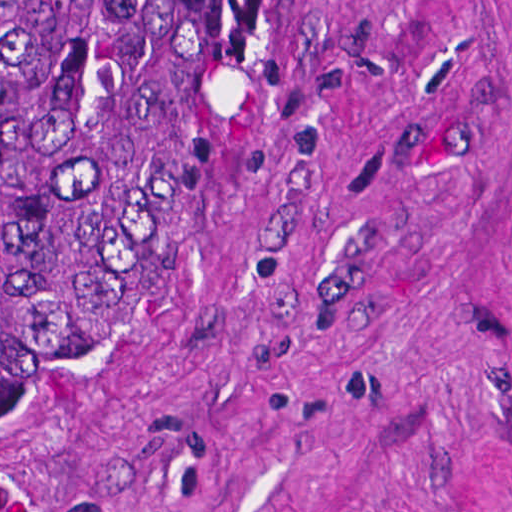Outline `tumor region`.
I'll list each match as a JSON object with an SVG mask.
<instances>
[{
  "instance_id": "tumor-region-1",
  "label": "tumor region",
  "mask_w": 512,
  "mask_h": 512,
  "mask_svg": "<svg viewBox=\"0 0 512 512\" xmlns=\"http://www.w3.org/2000/svg\"><path fill=\"white\" fill-rule=\"evenodd\" d=\"M213 0H0V384L126 280Z\"/></svg>"
}]
</instances>
